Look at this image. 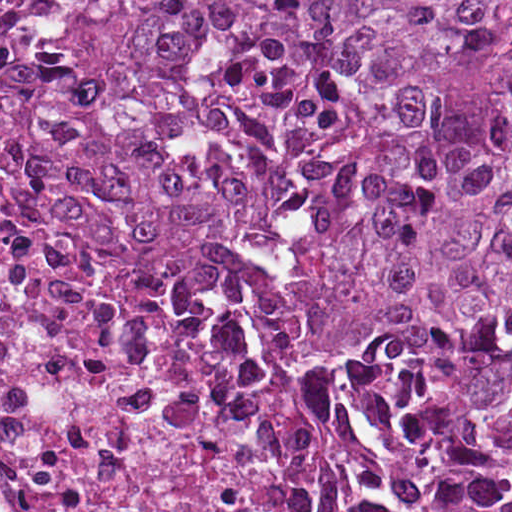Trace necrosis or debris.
Listing matches in <instances>:
<instances>
[{
	"instance_id": "obj_1",
	"label": "necrosis or debris",
	"mask_w": 512,
	"mask_h": 512,
	"mask_svg": "<svg viewBox=\"0 0 512 512\" xmlns=\"http://www.w3.org/2000/svg\"><path fill=\"white\" fill-rule=\"evenodd\" d=\"M81 1H0V512H415L131 272L69 244L34 137Z\"/></svg>"
}]
</instances>
